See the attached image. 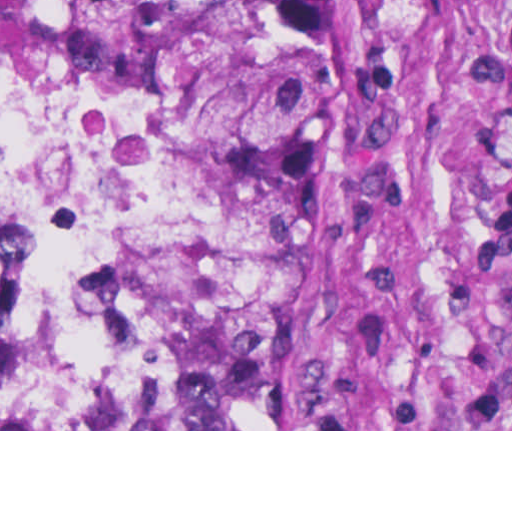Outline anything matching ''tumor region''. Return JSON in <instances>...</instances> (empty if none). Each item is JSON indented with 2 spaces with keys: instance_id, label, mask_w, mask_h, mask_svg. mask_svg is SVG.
Segmentation results:
<instances>
[{
  "instance_id": "1",
  "label": "tumor region",
  "mask_w": 512,
  "mask_h": 512,
  "mask_svg": "<svg viewBox=\"0 0 512 512\" xmlns=\"http://www.w3.org/2000/svg\"><path fill=\"white\" fill-rule=\"evenodd\" d=\"M386 0H0V69L185 114L233 152L252 244L213 284L179 387L0 429H277L334 273Z\"/></svg>"
}]
</instances>
